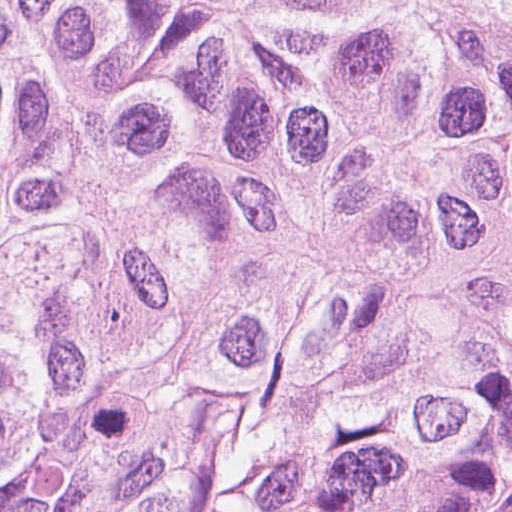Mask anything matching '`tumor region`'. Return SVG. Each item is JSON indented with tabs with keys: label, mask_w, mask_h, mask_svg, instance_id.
I'll list each match as a JSON object with an SVG mask.
<instances>
[{
	"label": "tumor region",
	"mask_w": 512,
	"mask_h": 512,
	"mask_svg": "<svg viewBox=\"0 0 512 512\" xmlns=\"http://www.w3.org/2000/svg\"><path fill=\"white\" fill-rule=\"evenodd\" d=\"M0 512H512V0H0Z\"/></svg>",
	"instance_id": "e687c5a6"
}]
</instances>
